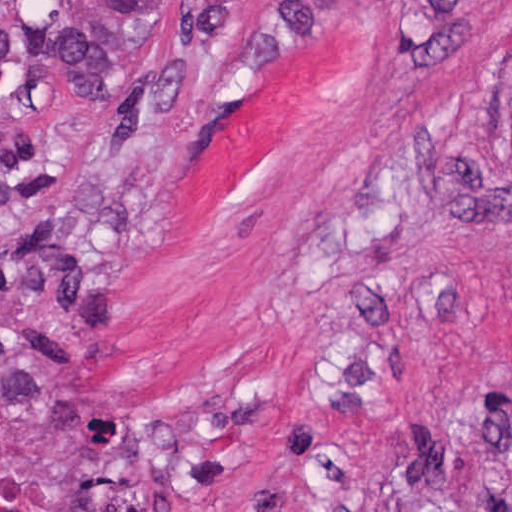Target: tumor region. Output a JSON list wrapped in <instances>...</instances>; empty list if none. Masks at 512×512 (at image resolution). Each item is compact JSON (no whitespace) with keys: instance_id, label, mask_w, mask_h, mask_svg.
Instances as JSON below:
<instances>
[{"instance_id":"obj_1","label":"tumor region","mask_w":512,"mask_h":512,"mask_svg":"<svg viewBox=\"0 0 512 512\" xmlns=\"http://www.w3.org/2000/svg\"><path fill=\"white\" fill-rule=\"evenodd\" d=\"M425 51L457 45L481 0H399ZM110 31L97 18H71L45 38L43 57L86 108L116 87ZM433 512H512V492Z\"/></svg>"}]
</instances>
